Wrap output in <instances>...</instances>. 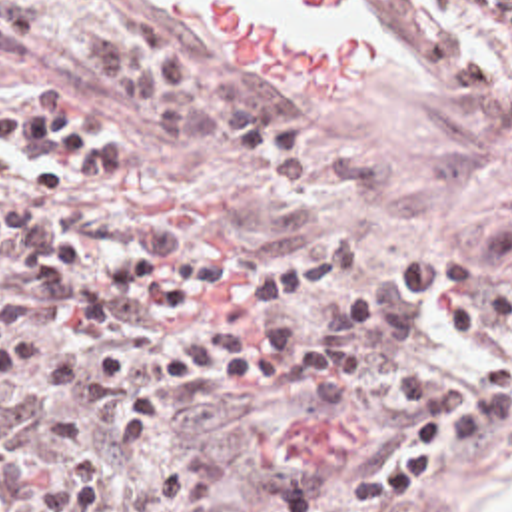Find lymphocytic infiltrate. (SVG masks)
<instances>
[{
    "mask_svg": "<svg viewBox=\"0 0 512 512\" xmlns=\"http://www.w3.org/2000/svg\"><path fill=\"white\" fill-rule=\"evenodd\" d=\"M75 48L107 110L187 152L219 156L239 192L293 194L318 180L309 134L267 118L245 84L197 66L145 12L83 32Z\"/></svg>",
    "mask_w": 512,
    "mask_h": 512,
    "instance_id": "obj_1",
    "label": "lymphocytic infiltrate"
}]
</instances>
